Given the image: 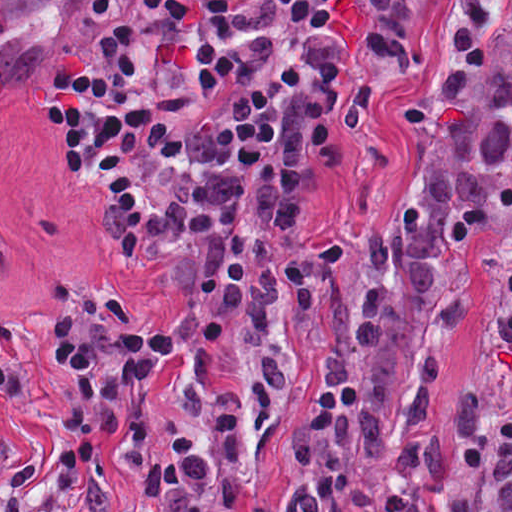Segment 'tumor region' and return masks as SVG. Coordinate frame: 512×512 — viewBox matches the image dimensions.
Here are the masks:
<instances>
[{
  "instance_id": "e687c5a6",
  "label": "tumor region",
  "mask_w": 512,
  "mask_h": 512,
  "mask_svg": "<svg viewBox=\"0 0 512 512\" xmlns=\"http://www.w3.org/2000/svg\"><path fill=\"white\" fill-rule=\"evenodd\" d=\"M432 3L373 0V60L424 66ZM491 222L506 227L482 368L512 420V0H452L451 48L420 100L408 180L367 234L359 309L330 254L276 259L238 330L165 388L215 419L216 442L207 452L200 435H181L149 463L154 512H265L264 433L304 366L288 463L306 512L447 451L436 404L461 259Z\"/></svg>"
}]
</instances>
